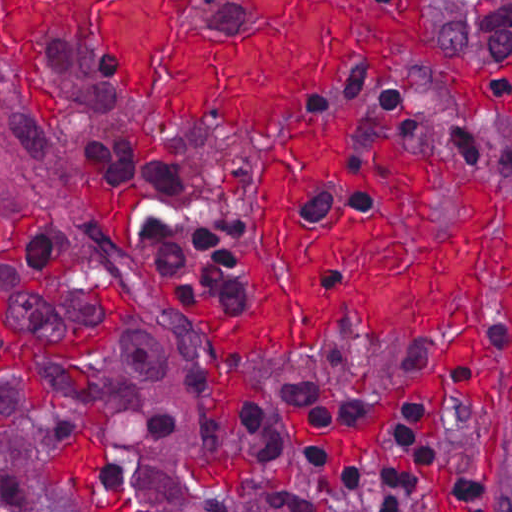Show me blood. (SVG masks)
Here are the masks:
<instances>
[{"label": "blood", "instance_id": "1a1defca", "mask_svg": "<svg viewBox=\"0 0 512 512\" xmlns=\"http://www.w3.org/2000/svg\"><path fill=\"white\" fill-rule=\"evenodd\" d=\"M258 29L246 41H214L180 11L178 0H1V54L21 66L37 113L55 115L46 51L53 37L71 34L111 63L145 98L186 119L258 135L278 144L262 157L259 183L264 233L244 251L242 267L257 304L249 312H219L202 294L175 308L216 341L206 397L209 417L235 429L240 403L262 395L261 385L234 366V353L271 351L309 356L340 308L363 314L382 336L436 338L460 329L431 374L387 385L373 413L348 425L308 426L293 413L294 440L324 447L327 484L343 461L370 450L386 459L383 431L398 404L435 405L424 433L439 436L447 376L457 390L493 407V389L512 348L487 345L478 326L494 319L485 277L503 281L502 315L512 334V193L503 235L490 234L494 195L484 180L456 187L463 217L453 236L432 235L434 165L447 183L457 168L444 154L421 155L394 146L390 133L414 120L416 109L365 114L341 106L312 122L298 118L322 102L347 67V46L389 71L404 49L442 58L445 38L428 0H256ZM101 331H81L62 343L44 338L1 354V378H27L42 389L35 359L74 364L99 359L131 319V303L102 287ZM473 321L475 325L464 326ZM512 415V386L508 393ZM108 423L86 410L77 445L49 462L52 482L73 480L90 512H129V500L96 499L98 449Z\"/></svg>", "mask_w": 512, "mask_h": 512}]
</instances>
